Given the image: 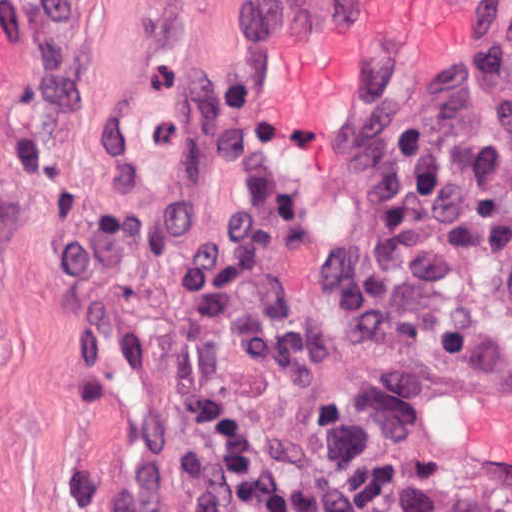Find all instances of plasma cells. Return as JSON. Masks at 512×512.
<instances>
[{
    "label": "plasma cells",
    "mask_w": 512,
    "mask_h": 512,
    "mask_svg": "<svg viewBox=\"0 0 512 512\" xmlns=\"http://www.w3.org/2000/svg\"><path fill=\"white\" fill-rule=\"evenodd\" d=\"M201 121L231 198L221 220L181 244L170 270L184 304L180 384L206 467L246 512H352L344 485L289 481L219 357L232 341L283 397L316 394L319 323L295 302L275 254L300 233L304 213L275 164L251 72L222 74ZM343 141L366 176V201L319 267L330 329L345 343L465 356L470 321L446 306L448 278L472 262L493 266L512 305V25L481 41L453 90L368 119Z\"/></svg>",
    "instance_id": "9512152a"
}]
</instances>
